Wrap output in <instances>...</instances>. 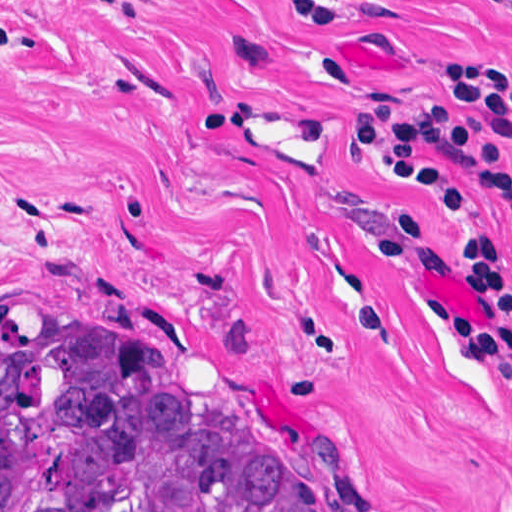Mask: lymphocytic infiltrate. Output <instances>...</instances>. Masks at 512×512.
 Returning a JSON list of instances; mask_svg holds the SVG:
<instances>
[{
	"instance_id": "obj_1",
	"label": "lymphocytic infiltrate",
	"mask_w": 512,
	"mask_h": 512,
	"mask_svg": "<svg viewBox=\"0 0 512 512\" xmlns=\"http://www.w3.org/2000/svg\"><path fill=\"white\" fill-rule=\"evenodd\" d=\"M512 10V0H498ZM304 21L352 23L346 0H296ZM351 153L403 184L447 223L458 272L472 303L453 308L417 286L409 252L417 220L392 206L376 252L397 272L412 313L467 345L512 401L502 338L512 336V270L494 247L483 206L455 170L502 207L512 227V67L485 55H446L423 70L411 92L382 97L345 124Z\"/></svg>"
}]
</instances>
